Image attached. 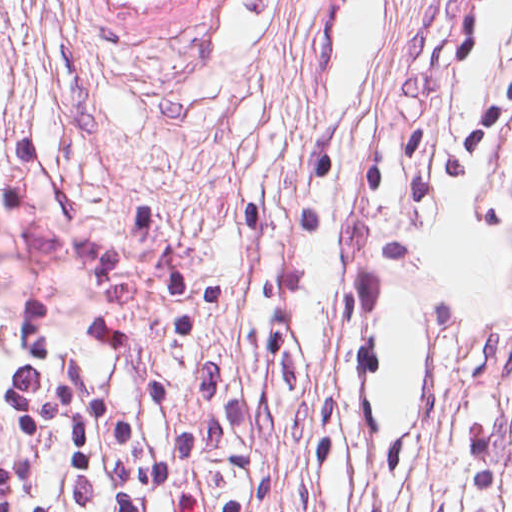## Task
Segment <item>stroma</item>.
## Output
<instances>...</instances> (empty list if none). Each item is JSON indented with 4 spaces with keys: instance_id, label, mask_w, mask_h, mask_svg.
I'll use <instances>...</instances> for the list:
<instances>
[{
    "instance_id": "obj_1",
    "label": "stroma",
    "mask_w": 512,
    "mask_h": 512,
    "mask_svg": "<svg viewBox=\"0 0 512 512\" xmlns=\"http://www.w3.org/2000/svg\"><path fill=\"white\" fill-rule=\"evenodd\" d=\"M447 12L223 0L178 47L128 53L80 0H0V303L169 363L212 512L472 510L512 308V226L488 242L512 220V144L432 214L288 225L307 156L446 122L512 59V0L476 66L421 59ZM507 430L500 512L512 408Z\"/></svg>"
}]
</instances>
